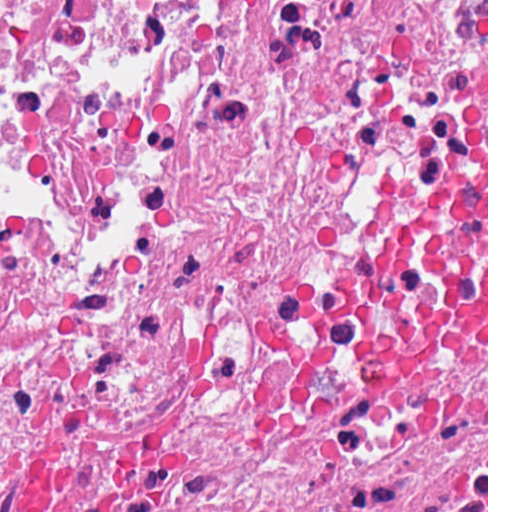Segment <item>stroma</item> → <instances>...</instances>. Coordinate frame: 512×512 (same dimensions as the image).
<instances>
[{
  "label": "stroma",
  "instance_id": "35a3bbf8",
  "mask_svg": "<svg viewBox=\"0 0 512 512\" xmlns=\"http://www.w3.org/2000/svg\"><path fill=\"white\" fill-rule=\"evenodd\" d=\"M438 512H488V0H486V448L455 469L438 421Z\"/></svg>",
  "mask_w": 512,
  "mask_h": 512
}]
</instances>
